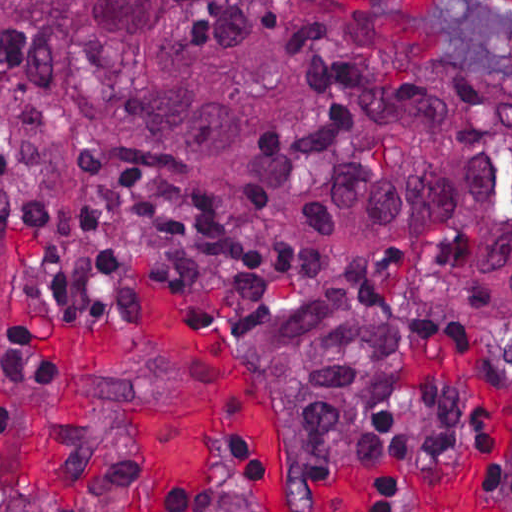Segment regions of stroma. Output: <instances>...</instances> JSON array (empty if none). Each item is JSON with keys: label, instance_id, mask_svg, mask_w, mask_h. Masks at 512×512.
<instances>
[{"label": "stroma", "instance_id": "obj_1", "mask_svg": "<svg viewBox=\"0 0 512 512\" xmlns=\"http://www.w3.org/2000/svg\"><path fill=\"white\" fill-rule=\"evenodd\" d=\"M319 18L363 28H388L409 44L512 89V12L486 0L414 32L392 18L355 11L345 0H301ZM0 185L45 191H100L175 206L216 220L252 239L265 255V287L247 339L248 314L230 323L197 303L178 268L156 256H130L119 297L108 312H75L28 301L18 279L13 234L0 218V310L12 325H29L62 348L77 377L54 391H27L0 376V512H142V430L151 414L192 417L200 392L189 364L146 328L138 312L142 282H153L217 335L245 367L272 435L288 465L318 475L353 478L367 512H385L409 484L436 473H468L474 490L461 512H512V486L486 485L477 434L492 412L512 403V325L472 315L464 323H431L409 353L412 383L451 382L471 406L469 442L457 453L394 469L368 463H310L290 446L282 402L259 347L261 320L277 305L341 276L351 257L310 250L286 233L240 223L187 192L164 189L82 166L52 168L35 147L0 121ZM258 459L249 445L228 440L211 459L210 512H256ZM404 512H426L410 492Z\"/></svg>", "mask_w": 512, "mask_h": 512}]
</instances>
